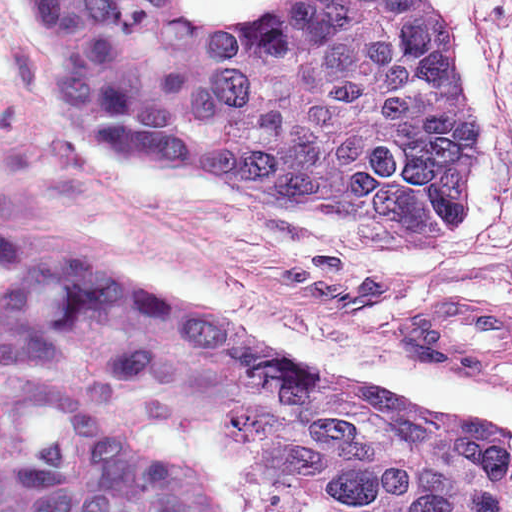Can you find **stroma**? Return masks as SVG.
I'll return each mask as SVG.
<instances>
[{"instance_id": "stroma-1", "label": "stroma", "mask_w": 512, "mask_h": 512, "mask_svg": "<svg viewBox=\"0 0 512 512\" xmlns=\"http://www.w3.org/2000/svg\"><path fill=\"white\" fill-rule=\"evenodd\" d=\"M512 77V0H478Z\"/></svg>"}]
</instances>
